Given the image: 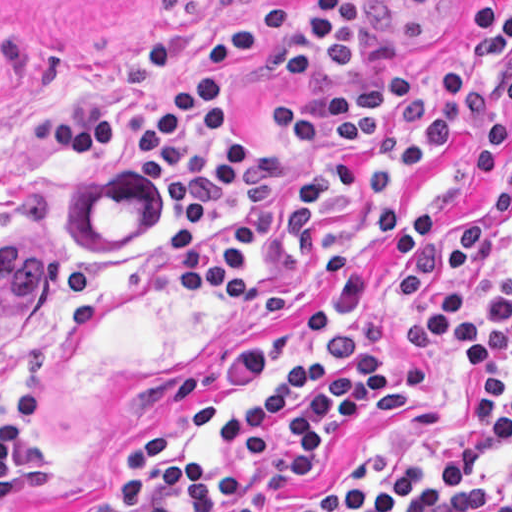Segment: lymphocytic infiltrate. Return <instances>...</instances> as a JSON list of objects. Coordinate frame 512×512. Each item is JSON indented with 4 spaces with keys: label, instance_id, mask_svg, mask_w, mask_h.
<instances>
[{
    "label": "lymphocytic infiltrate",
    "instance_id": "obj_1",
    "mask_svg": "<svg viewBox=\"0 0 512 512\" xmlns=\"http://www.w3.org/2000/svg\"><path fill=\"white\" fill-rule=\"evenodd\" d=\"M470 39L473 68L446 66L431 86L412 69L284 103L268 155L256 151L229 107L241 67L265 61L279 81H328L357 66L366 43V0H270L208 37L201 78L180 70L171 32L135 37L136 63L157 75L140 120H127L116 96L90 92L30 108L28 137L37 148L97 152L166 196L181 224L167 228L162 250L183 300L209 291L243 318H280L298 298L282 278L290 268L310 261L311 288H340L366 234L391 256L397 314L444 263L438 210L396 219L402 195L457 134L474 175L496 178L505 163L489 81L499 74L512 104V11L495 17L492 3L474 1ZM366 340L362 324L333 326L217 418L221 444L245 449V462L282 453L284 474L316 461L360 405L403 389L398 367L364 350ZM439 341L450 343L462 366L476 367L457 438L421 466L317 491L283 512H512V474L496 483L484 477L512 445V265L508 286L478 324L458 277L430 289L416 321L404 326L402 353L416 356ZM44 414L35 375L0 418V501L45 479L48 451L33 435ZM174 443L172 428L146 426L128 448L114 492L76 512H251L256 482L168 459Z\"/></svg>",
    "mask_w": 512,
    "mask_h": 512
}]
</instances>
